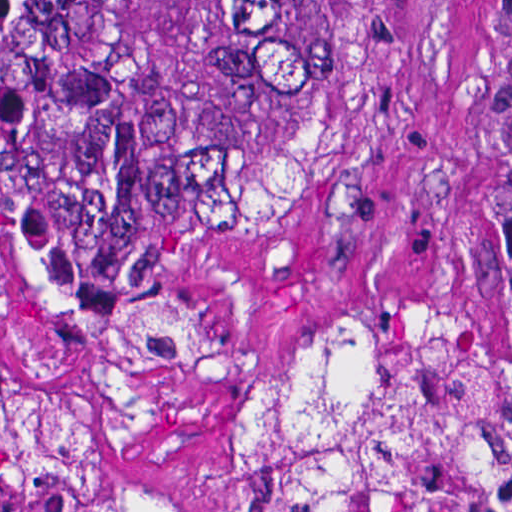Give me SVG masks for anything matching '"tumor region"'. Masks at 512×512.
<instances>
[{
  "mask_svg": "<svg viewBox=\"0 0 512 512\" xmlns=\"http://www.w3.org/2000/svg\"><path fill=\"white\" fill-rule=\"evenodd\" d=\"M380 0H0V239L82 353L0 364V512H160L95 479L99 436L222 370L169 266L254 243L332 163L371 87ZM257 512H512V342L424 296L332 298L253 360Z\"/></svg>",
  "mask_w": 512,
  "mask_h": 512,
  "instance_id": "1",
  "label": "tumor region"
}]
</instances>
